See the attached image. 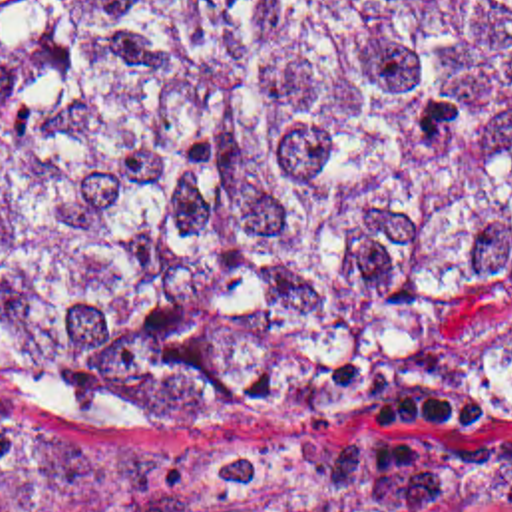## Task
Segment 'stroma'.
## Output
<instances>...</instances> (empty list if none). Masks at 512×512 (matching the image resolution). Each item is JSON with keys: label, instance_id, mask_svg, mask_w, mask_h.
<instances>
[{"label": "stroma", "instance_id": "1", "mask_svg": "<svg viewBox=\"0 0 512 512\" xmlns=\"http://www.w3.org/2000/svg\"><path fill=\"white\" fill-rule=\"evenodd\" d=\"M428 425L400 449L280 451L179 431H115L49 387L0 373V419L53 431L155 439L211 449H257L272 455H428L474 465H512V282L458 286L424 332ZM368 512H512L494 505H396Z\"/></svg>", "mask_w": 512, "mask_h": 512}]
</instances>
